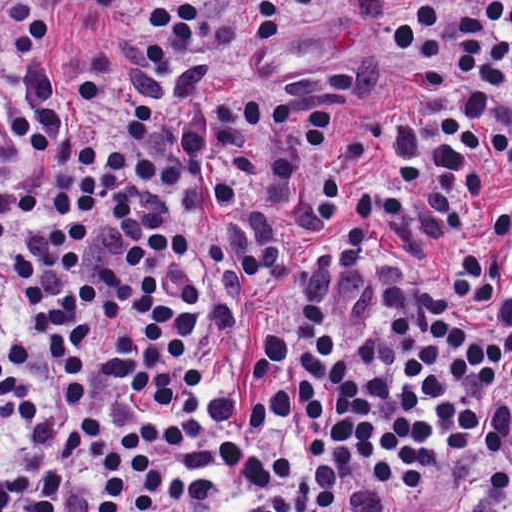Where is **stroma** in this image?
<instances>
[{"instance_id":"35a3bbf8","label":"stroma","mask_w":512,"mask_h":512,"mask_svg":"<svg viewBox=\"0 0 512 512\" xmlns=\"http://www.w3.org/2000/svg\"><path fill=\"white\" fill-rule=\"evenodd\" d=\"M67 1L81 5L59 18L115 39L135 25L144 1L175 0ZM404 1L512 0H290L294 31L285 44L277 50L261 49L258 41L228 29L222 42L221 66L237 84L256 93L287 85L316 65L347 59L355 71L348 114L352 126L410 121L414 114L425 118L408 95L403 65L388 33L393 11ZM38 31L43 38V23ZM497 470H512V427L480 450L467 469L429 502L412 512H437L444 496Z\"/></svg>"}]
</instances>
